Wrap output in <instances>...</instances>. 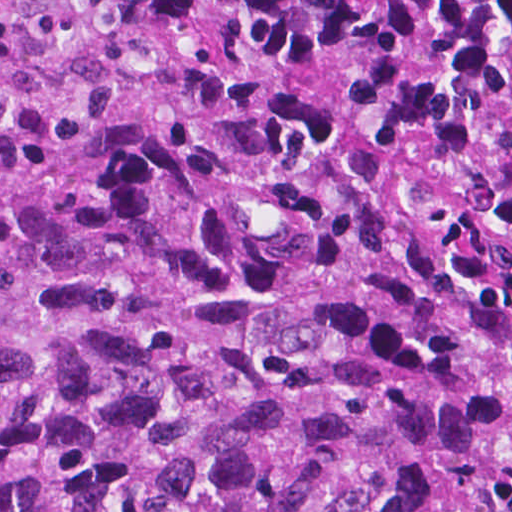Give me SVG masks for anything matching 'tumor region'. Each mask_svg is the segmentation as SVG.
<instances>
[{"instance_id":"e687c5a6","label":"tumor region","mask_w":512,"mask_h":512,"mask_svg":"<svg viewBox=\"0 0 512 512\" xmlns=\"http://www.w3.org/2000/svg\"><path fill=\"white\" fill-rule=\"evenodd\" d=\"M0 512H512V0H0Z\"/></svg>"}]
</instances>
